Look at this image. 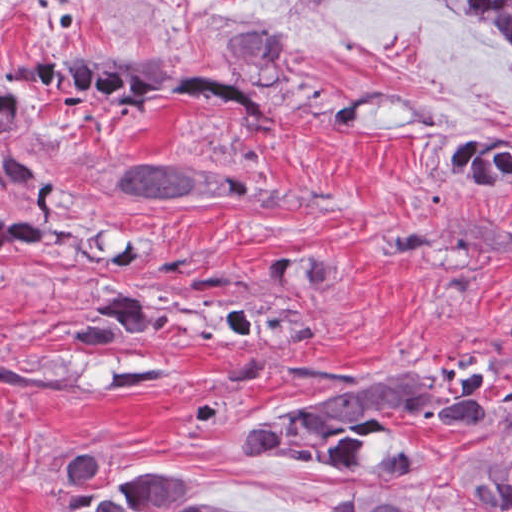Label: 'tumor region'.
<instances>
[{
    "label": "tumor region",
    "mask_w": 512,
    "mask_h": 512,
    "mask_svg": "<svg viewBox=\"0 0 512 512\" xmlns=\"http://www.w3.org/2000/svg\"><path fill=\"white\" fill-rule=\"evenodd\" d=\"M309 2L314 0H308ZM488 29L512 59V0H420ZM225 76L130 70L122 53L85 60H20L0 86V181L39 200L25 220H0V279L10 270L102 265L124 253L145 229L89 200L30 153L36 127L64 103L121 115L130 125L152 126L185 107H203L255 137H275L283 122L273 95L329 123L357 125L371 100L329 82L294 78L291 36L244 26L229 38ZM136 150L108 174L110 185L141 204L185 211L221 201L257 197L291 211H331L332 205L282 188L248 183L234 174L182 164ZM440 174L482 201L512 197V118L474 120L446 130L434 149ZM392 265L424 263L440 255L512 264V226L502 221L452 217L441 229L405 225L370 244ZM343 272L332 248L298 247L279 253L260 284L239 276L224 295L199 296L162 282L105 279L90 312L69 339L123 344L148 335H230L275 359H290L327 327L325 296ZM0 340V386L90 393L87 377L18 366ZM180 370L166 362L120 355L103 393H143L173 383ZM512 406V389L484 388L462 366L403 373L353 387L331 398L271 414L248 428L255 454L305 463L326 471L385 476L414 465L417 452L388 420L405 415L467 430ZM104 460L86 458L66 478L48 512H255L197 497L195 476L168 471L131 473L105 486L95 479ZM474 502L491 512H512V449L492 465L461 476ZM339 512H421L413 497L347 494Z\"/></svg>",
    "instance_id": "obj_1"
}]
</instances>
